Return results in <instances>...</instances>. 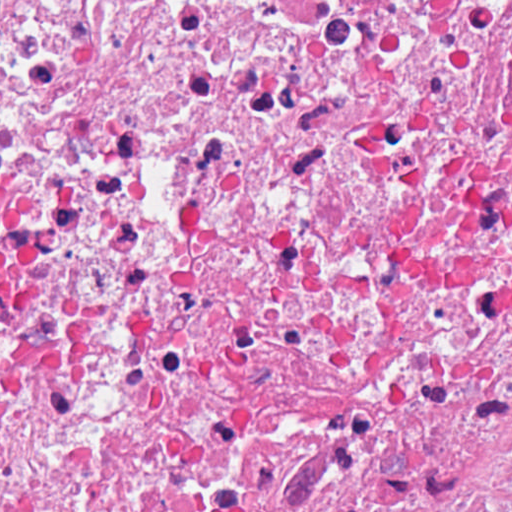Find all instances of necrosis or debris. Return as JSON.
<instances>
[{
  "label": "necrosis or debris",
  "instance_id": "1",
  "mask_svg": "<svg viewBox=\"0 0 512 512\" xmlns=\"http://www.w3.org/2000/svg\"><path fill=\"white\" fill-rule=\"evenodd\" d=\"M0 512H512V0H0Z\"/></svg>",
  "mask_w": 512,
  "mask_h": 512
}]
</instances>
